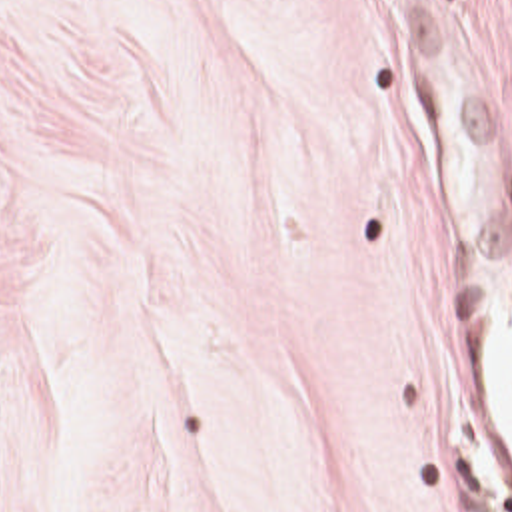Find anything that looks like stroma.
Segmentation results:
<instances>
[{
  "label": "stroma",
  "mask_w": 512,
  "mask_h": 512,
  "mask_svg": "<svg viewBox=\"0 0 512 512\" xmlns=\"http://www.w3.org/2000/svg\"><path fill=\"white\" fill-rule=\"evenodd\" d=\"M0 512H512V0H0Z\"/></svg>",
  "instance_id": "1"
}]
</instances>
